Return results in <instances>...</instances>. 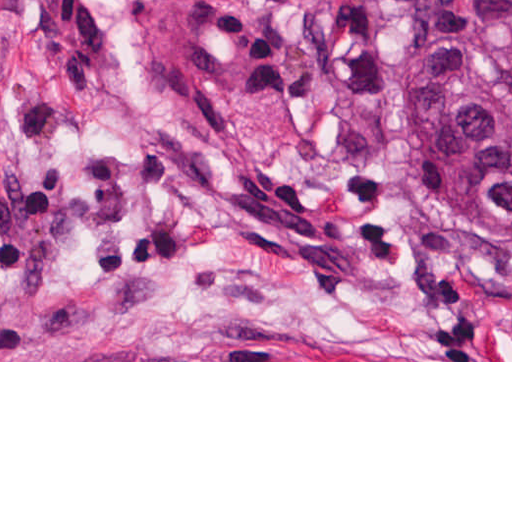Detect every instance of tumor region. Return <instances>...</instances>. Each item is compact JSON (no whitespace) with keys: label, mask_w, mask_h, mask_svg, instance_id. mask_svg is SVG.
<instances>
[{"label":"tumor region","mask_w":512,"mask_h":512,"mask_svg":"<svg viewBox=\"0 0 512 512\" xmlns=\"http://www.w3.org/2000/svg\"><path fill=\"white\" fill-rule=\"evenodd\" d=\"M379 1L407 222L455 274H512V0Z\"/></svg>","instance_id":"e687c5a6"}]
</instances>
